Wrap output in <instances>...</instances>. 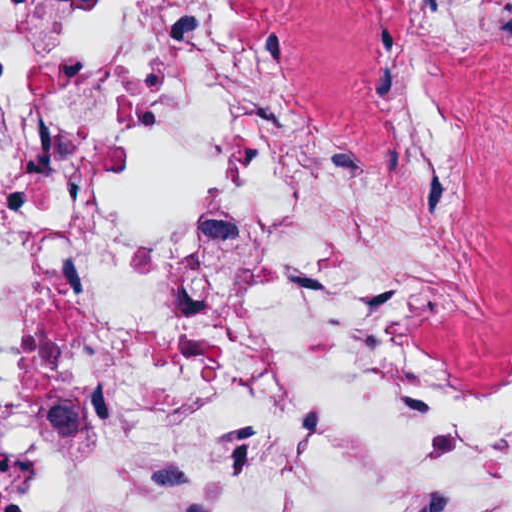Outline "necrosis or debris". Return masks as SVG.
<instances>
[{
  "label": "necrosis or debris",
  "mask_w": 512,
  "mask_h": 512,
  "mask_svg": "<svg viewBox=\"0 0 512 512\" xmlns=\"http://www.w3.org/2000/svg\"><path fill=\"white\" fill-rule=\"evenodd\" d=\"M0 512H512V0H0Z\"/></svg>",
  "instance_id": "necrosis-or-debris-1"
}]
</instances>
